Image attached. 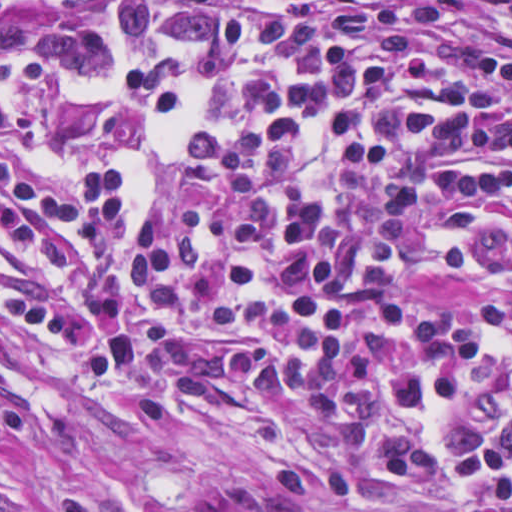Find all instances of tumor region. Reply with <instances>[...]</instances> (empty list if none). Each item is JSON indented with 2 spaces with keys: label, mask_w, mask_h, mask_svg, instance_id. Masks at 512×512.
<instances>
[{
  "label": "tumor region",
  "mask_w": 512,
  "mask_h": 512,
  "mask_svg": "<svg viewBox=\"0 0 512 512\" xmlns=\"http://www.w3.org/2000/svg\"><path fill=\"white\" fill-rule=\"evenodd\" d=\"M103 0H1V18H43L65 8Z\"/></svg>",
  "instance_id": "1"
}]
</instances>
